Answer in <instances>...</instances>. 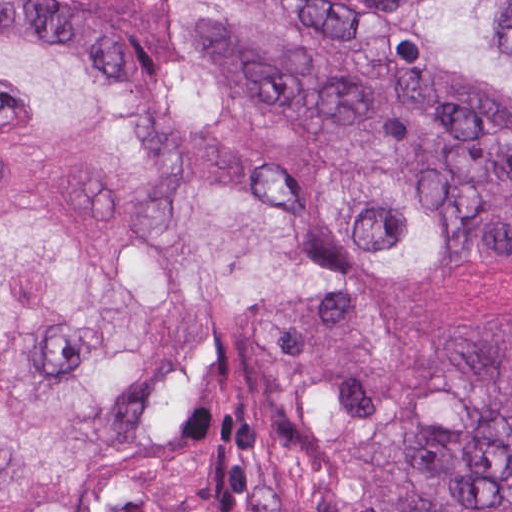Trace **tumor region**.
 I'll return each mask as SVG.
<instances>
[{
	"label": "tumor region",
	"instance_id": "1",
	"mask_svg": "<svg viewBox=\"0 0 512 512\" xmlns=\"http://www.w3.org/2000/svg\"><path fill=\"white\" fill-rule=\"evenodd\" d=\"M183 1L294 136L430 173L469 198L483 237L512 245V117L394 94L293 0ZM362 1L425 56L512 89V0ZM166 23L182 249L249 314L301 440L336 446L386 372L366 276L449 253V213L258 141ZM0 32L142 55L135 23L95 0H0ZM169 171L154 120L77 59L0 41V512H88L138 469L163 395L217 349L159 229ZM401 405L358 449L383 512H512V406Z\"/></svg>",
	"mask_w": 512,
	"mask_h": 512
}]
</instances>
